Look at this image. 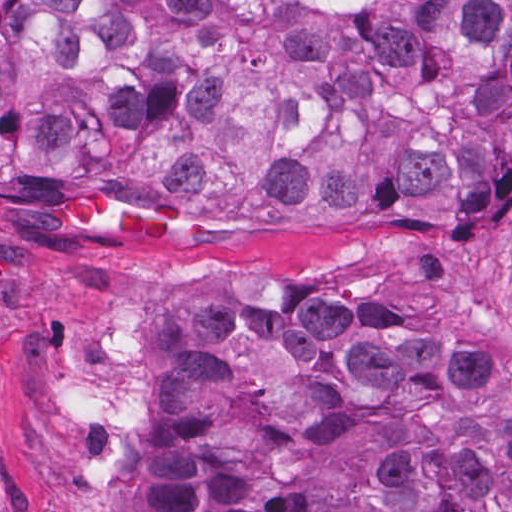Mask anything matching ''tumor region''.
<instances>
[{
	"label": "tumor region",
	"instance_id": "obj_1",
	"mask_svg": "<svg viewBox=\"0 0 512 512\" xmlns=\"http://www.w3.org/2000/svg\"><path fill=\"white\" fill-rule=\"evenodd\" d=\"M512 172V0H0V193L455 219ZM224 420L146 432L132 512H512L511 363L275 286L143 346Z\"/></svg>",
	"mask_w": 512,
	"mask_h": 512
}]
</instances>
